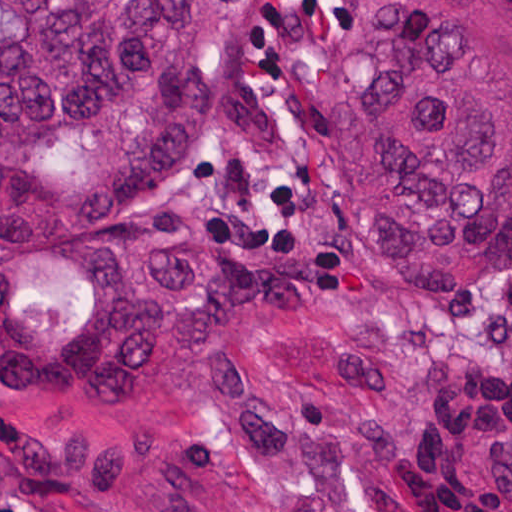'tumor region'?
<instances>
[{"instance_id": "obj_1", "label": "tumor region", "mask_w": 512, "mask_h": 512, "mask_svg": "<svg viewBox=\"0 0 512 512\" xmlns=\"http://www.w3.org/2000/svg\"><path fill=\"white\" fill-rule=\"evenodd\" d=\"M256 0H0V256L138 213ZM352 0L321 77L343 235H104L70 322L0 353L15 512H408L394 294L512 270V0Z\"/></svg>"}]
</instances>
